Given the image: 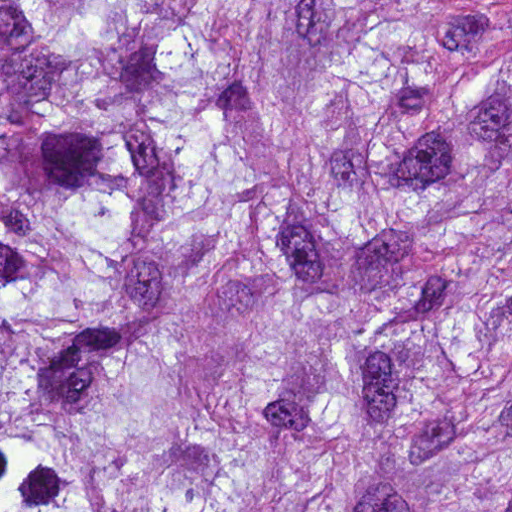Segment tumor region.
<instances>
[{
  "mask_svg": "<svg viewBox=\"0 0 512 512\" xmlns=\"http://www.w3.org/2000/svg\"><path fill=\"white\" fill-rule=\"evenodd\" d=\"M0 512H512V1H0Z\"/></svg>",
  "mask_w": 512,
  "mask_h": 512,
  "instance_id": "tumor-region-1",
  "label": "tumor region"
}]
</instances>
